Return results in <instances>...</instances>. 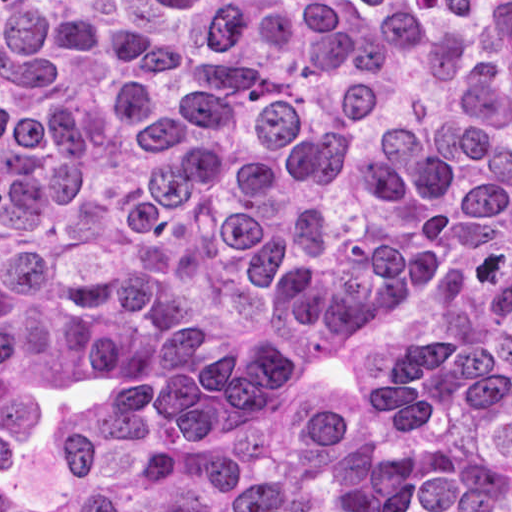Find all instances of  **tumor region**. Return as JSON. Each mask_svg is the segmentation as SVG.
Listing matches in <instances>:
<instances>
[{
    "mask_svg": "<svg viewBox=\"0 0 512 512\" xmlns=\"http://www.w3.org/2000/svg\"><path fill=\"white\" fill-rule=\"evenodd\" d=\"M0 512H512V0H0Z\"/></svg>",
    "mask_w": 512,
    "mask_h": 512,
    "instance_id": "tumor-region-1",
    "label": "tumor region"
}]
</instances>
